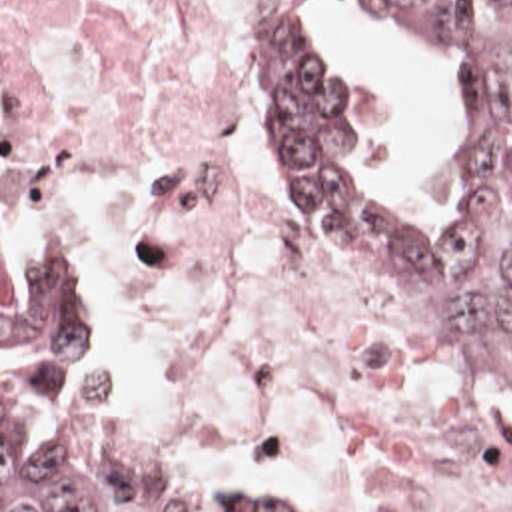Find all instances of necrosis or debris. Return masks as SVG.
<instances>
[{
  "label": "necrosis or debris",
  "mask_w": 512,
  "mask_h": 512,
  "mask_svg": "<svg viewBox=\"0 0 512 512\" xmlns=\"http://www.w3.org/2000/svg\"><path fill=\"white\" fill-rule=\"evenodd\" d=\"M298 3L2 0V197L84 261L108 437L302 512H512L497 405L333 269L284 179Z\"/></svg>",
  "instance_id": "1"
}]
</instances>
